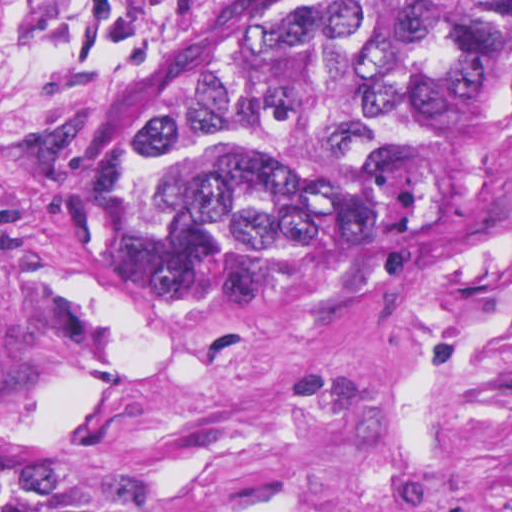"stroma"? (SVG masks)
Here are the masks:
<instances>
[{"mask_svg": "<svg viewBox=\"0 0 512 512\" xmlns=\"http://www.w3.org/2000/svg\"><path fill=\"white\" fill-rule=\"evenodd\" d=\"M253 0H0V387L133 512H512V123L392 271L131 265L110 105Z\"/></svg>", "mask_w": 512, "mask_h": 512, "instance_id": "stroma-1", "label": "stroma"}]
</instances>
